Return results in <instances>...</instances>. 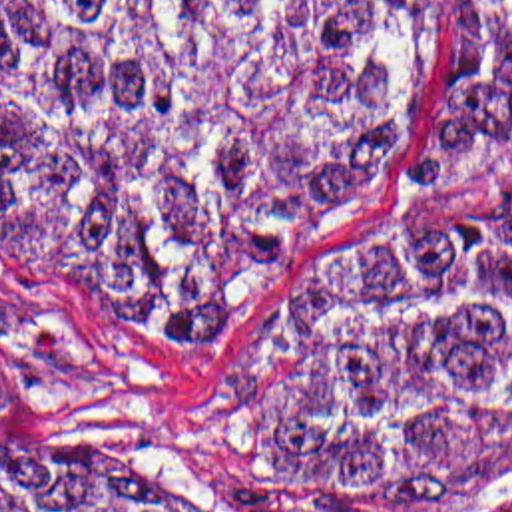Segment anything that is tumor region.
Returning <instances> with one entry per match:
<instances>
[{
  "instance_id": "e687c5a6",
  "label": "tumor region",
  "mask_w": 512,
  "mask_h": 512,
  "mask_svg": "<svg viewBox=\"0 0 512 512\" xmlns=\"http://www.w3.org/2000/svg\"><path fill=\"white\" fill-rule=\"evenodd\" d=\"M422 36L424 0H0V255L231 346L187 424L293 512H476L512 476V0H446L409 191L307 276ZM26 388L0 352V428Z\"/></svg>"
}]
</instances>
